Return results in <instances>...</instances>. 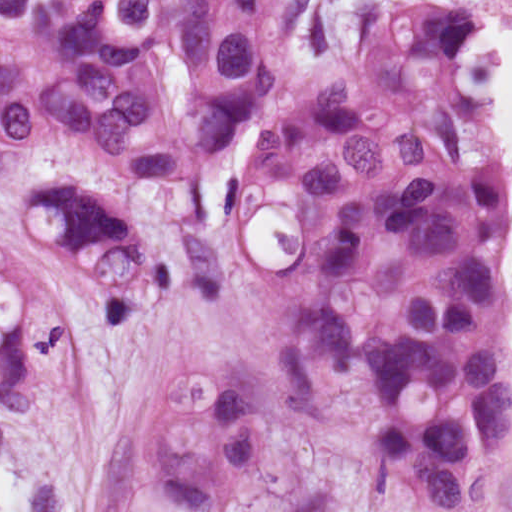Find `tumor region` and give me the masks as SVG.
Listing matches in <instances>:
<instances>
[{"label": "tumor region", "mask_w": 512, "mask_h": 512, "mask_svg": "<svg viewBox=\"0 0 512 512\" xmlns=\"http://www.w3.org/2000/svg\"><path fill=\"white\" fill-rule=\"evenodd\" d=\"M301 0H134L0 60V170L37 148H89L112 173L185 180L207 225L223 149L296 82ZM478 21L418 4L381 21L361 63L298 95L240 150L216 208L238 224L272 202L301 251L273 278L291 296L279 339L289 406L329 445L439 510H474L512 424L511 240L493 114L464 96ZM25 217L131 326L172 291L112 195L41 181ZM71 318L41 276L0 251V405L31 423L54 400ZM227 367L153 386L105 512H242L256 466V386Z\"/></svg>", "instance_id": "obj_1"}]
</instances>
